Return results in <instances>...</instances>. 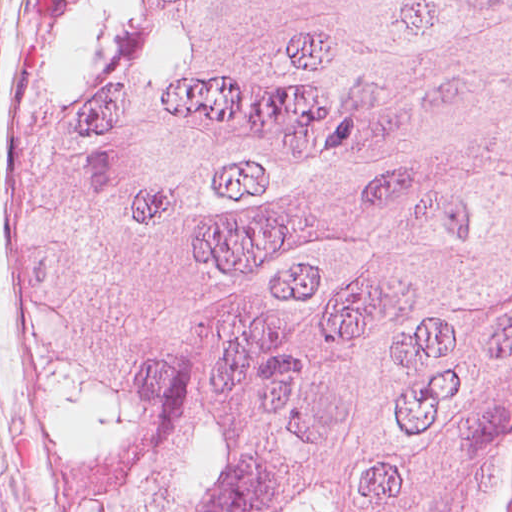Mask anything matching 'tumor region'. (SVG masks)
Wrapping results in <instances>:
<instances>
[{
    "mask_svg": "<svg viewBox=\"0 0 512 512\" xmlns=\"http://www.w3.org/2000/svg\"><path fill=\"white\" fill-rule=\"evenodd\" d=\"M37 378L77 512H471L512 392V0H44Z\"/></svg>",
    "mask_w": 512,
    "mask_h": 512,
    "instance_id": "obj_1",
    "label": "tumor region"
}]
</instances>
